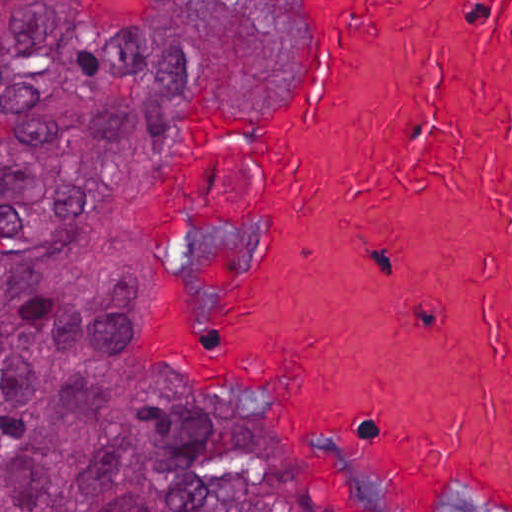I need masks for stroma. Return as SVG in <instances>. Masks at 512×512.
I'll return each mask as SVG.
<instances>
[{
    "label": "stroma",
    "instance_id": "stroma-1",
    "mask_svg": "<svg viewBox=\"0 0 512 512\" xmlns=\"http://www.w3.org/2000/svg\"><path fill=\"white\" fill-rule=\"evenodd\" d=\"M78 16L120 27H150L180 19L199 0H63ZM289 40L264 89H244L226 75L179 77L153 111L146 155L130 216V242L158 260H215L233 268V291H204L165 269L148 275L130 313V360L148 376L245 394L253 412L247 431L271 445L291 476L301 512H344L296 445L290 420L301 407L291 389L263 375L191 372L165 343L156 309L174 305L204 326H226L253 303V284L269 235L266 217H246L203 241L153 227L146 212L158 183L162 153L180 116L225 123L284 121L301 110L322 57L308 0H288ZM485 507V506H458ZM445 510V509H442ZM488 512H497L490 510Z\"/></svg>",
    "mask_w": 512,
    "mask_h": 512
}]
</instances>
